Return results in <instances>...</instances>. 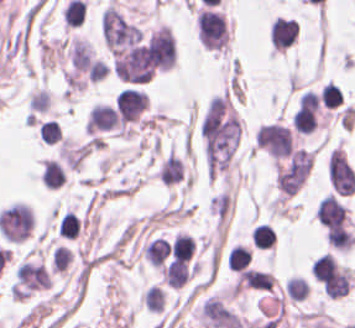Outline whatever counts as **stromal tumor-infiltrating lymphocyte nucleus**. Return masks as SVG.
<instances>
[{
	"instance_id": "9ea309e8",
	"label": "stromal tumor-infiltrating lymphocyte nucleus",
	"mask_w": 355,
	"mask_h": 328,
	"mask_svg": "<svg viewBox=\"0 0 355 328\" xmlns=\"http://www.w3.org/2000/svg\"><path fill=\"white\" fill-rule=\"evenodd\" d=\"M192 252V240L185 234H178L170 245L171 258H179L190 261Z\"/></svg>"
},
{
	"instance_id": "52c7bb5b",
	"label": "stromal tumor-infiltrating lymphocyte nucleus",
	"mask_w": 355,
	"mask_h": 328,
	"mask_svg": "<svg viewBox=\"0 0 355 328\" xmlns=\"http://www.w3.org/2000/svg\"><path fill=\"white\" fill-rule=\"evenodd\" d=\"M346 206L335 196L328 195L316 208V218L325 229L332 230L345 224Z\"/></svg>"
},
{
	"instance_id": "4803ca6d",
	"label": "stromal tumor-infiltrating lymphocyte nucleus",
	"mask_w": 355,
	"mask_h": 328,
	"mask_svg": "<svg viewBox=\"0 0 355 328\" xmlns=\"http://www.w3.org/2000/svg\"><path fill=\"white\" fill-rule=\"evenodd\" d=\"M61 130L53 121V119L41 122L39 126V136L44 142L54 143L57 142Z\"/></svg>"
},
{
	"instance_id": "3290ff9b",
	"label": "stromal tumor-infiltrating lymphocyte nucleus",
	"mask_w": 355,
	"mask_h": 328,
	"mask_svg": "<svg viewBox=\"0 0 355 328\" xmlns=\"http://www.w3.org/2000/svg\"><path fill=\"white\" fill-rule=\"evenodd\" d=\"M252 260V252L250 249L242 246L235 245L231 247L228 254V268L232 271H243L248 268Z\"/></svg>"
},
{
	"instance_id": "2a367800",
	"label": "stromal tumor-infiltrating lymphocyte nucleus",
	"mask_w": 355,
	"mask_h": 328,
	"mask_svg": "<svg viewBox=\"0 0 355 328\" xmlns=\"http://www.w3.org/2000/svg\"><path fill=\"white\" fill-rule=\"evenodd\" d=\"M320 100L324 107L336 108L342 102V91L330 80L320 90Z\"/></svg>"
},
{
	"instance_id": "bc302bb0",
	"label": "stromal tumor-infiltrating lymphocyte nucleus",
	"mask_w": 355,
	"mask_h": 328,
	"mask_svg": "<svg viewBox=\"0 0 355 328\" xmlns=\"http://www.w3.org/2000/svg\"><path fill=\"white\" fill-rule=\"evenodd\" d=\"M147 102L145 92L124 87L115 97L114 107L120 121L131 122L139 116Z\"/></svg>"
},
{
	"instance_id": "4f13568d",
	"label": "stromal tumor-infiltrating lymphocyte nucleus",
	"mask_w": 355,
	"mask_h": 328,
	"mask_svg": "<svg viewBox=\"0 0 355 328\" xmlns=\"http://www.w3.org/2000/svg\"><path fill=\"white\" fill-rule=\"evenodd\" d=\"M326 236L329 245L337 251H347L353 241L351 232L342 229L330 227Z\"/></svg>"
},
{
	"instance_id": "f3e2335f",
	"label": "stromal tumor-infiltrating lymphocyte nucleus",
	"mask_w": 355,
	"mask_h": 328,
	"mask_svg": "<svg viewBox=\"0 0 355 328\" xmlns=\"http://www.w3.org/2000/svg\"><path fill=\"white\" fill-rule=\"evenodd\" d=\"M251 239L254 246L265 250L272 246L276 236L272 226L258 224L252 232Z\"/></svg>"
},
{
	"instance_id": "abfb95fc",
	"label": "stromal tumor-infiltrating lymphocyte nucleus",
	"mask_w": 355,
	"mask_h": 328,
	"mask_svg": "<svg viewBox=\"0 0 355 328\" xmlns=\"http://www.w3.org/2000/svg\"><path fill=\"white\" fill-rule=\"evenodd\" d=\"M80 227L81 221L67 210L60 218L57 233L58 236L73 240L78 236Z\"/></svg>"
}]
</instances>
